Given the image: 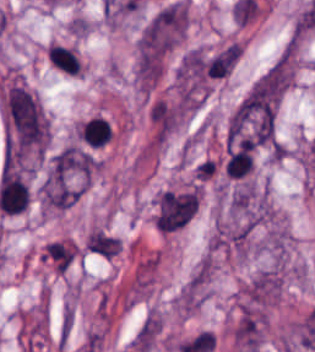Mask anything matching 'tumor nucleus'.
<instances>
[{
    "instance_id": "1",
    "label": "tumor nucleus",
    "mask_w": 315,
    "mask_h": 352,
    "mask_svg": "<svg viewBox=\"0 0 315 352\" xmlns=\"http://www.w3.org/2000/svg\"><path fill=\"white\" fill-rule=\"evenodd\" d=\"M187 26L184 0L164 5L144 26L138 40L142 57H158L172 48Z\"/></svg>"
}]
</instances>
